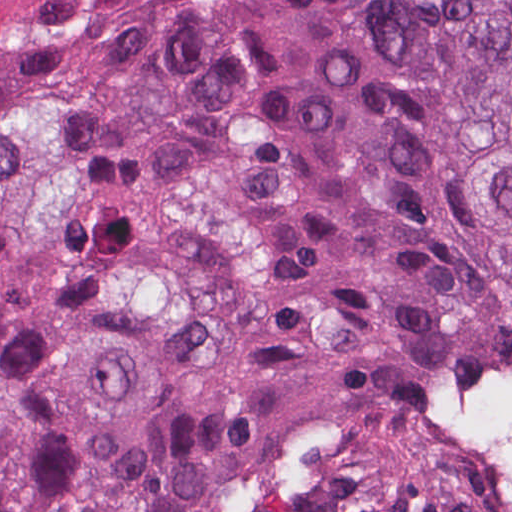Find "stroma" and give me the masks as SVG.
<instances>
[{
	"mask_svg": "<svg viewBox=\"0 0 512 512\" xmlns=\"http://www.w3.org/2000/svg\"><path fill=\"white\" fill-rule=\"evenodd\" d=\"M512 386V361L485 396ZM448 483L466 512H512V451L459 437Z\"/></svg>",
	"mask_w": 512,
	"mask_h": 512,
	"instance_id": "obj_1",
	"label": "stroma"
}]
</instances>
